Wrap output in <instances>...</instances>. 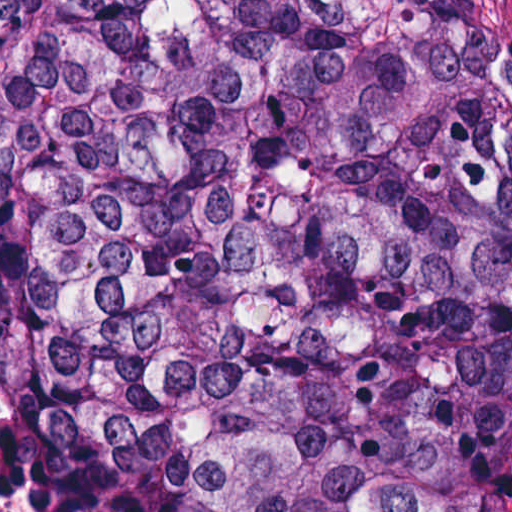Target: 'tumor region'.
Segmentation results:
<instances>
[{
	"label": "tumor region",
	"mask_w": 512,
	"mask_h": 512,
	"mask_svg": "<svg viewBox=\"0 0 512 512\" xmlns=\"http://www.w3.org/2000/svg\"><path fill=\"white\" fill-rule=\"evenodd\" d=\"M0 383L44 512H512V24L0 1Z\"/></svg>",
	"instance_id": "obj_1"
}]
</instances>
